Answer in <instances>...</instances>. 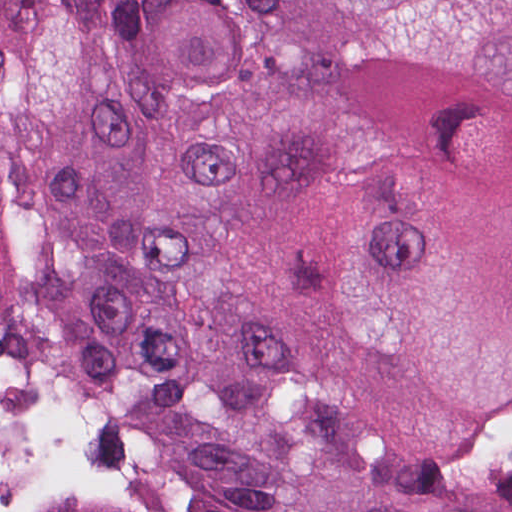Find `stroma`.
Segmentation results:
<instances>
[{
	"mask_svg": "<svg viewBox=\"0 0 512 512\" xmlns=\"http://www.w3.org/2000/svg\"><path fill=\"white\" fill-rule=\"evenodd\" d=\"M0 373L43 393L75 419L110 431L126 448L144 458L152 475V497L111 499L56 488L39 498L29 512H184L168 467L146 433L62 397L14 345L1 337Z\"/></svg>",
	"mask_w": 512,
	"mask_h": 512,
	"instance_id": "obj_1",
	"label": "stroma"
}]
</instances>
